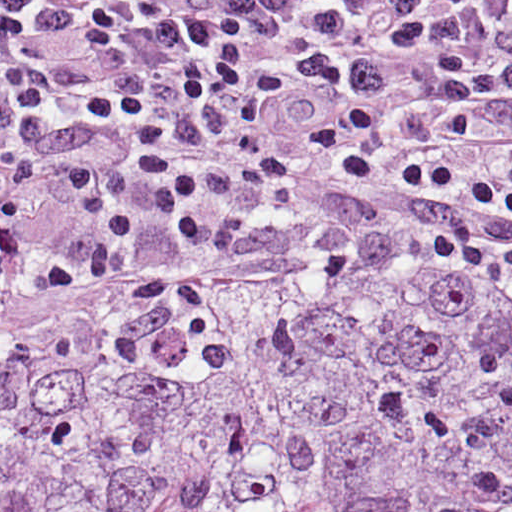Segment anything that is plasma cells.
I'll return each instance as SVG.
<instances>
[{"label":"plasma cells","mask_w":512,"mask_h":512,"mask_svg":"<svg viewBox=\"0 0 512 512\" xmlns=\"http://www.w3.org/2000/svg\"><path fill=\"white\" fill-rule=\"evenodd\" d=\"M92 216L512 269V0H0V252Z\"/></svg>","instance_id":"1"}]
</instances>
